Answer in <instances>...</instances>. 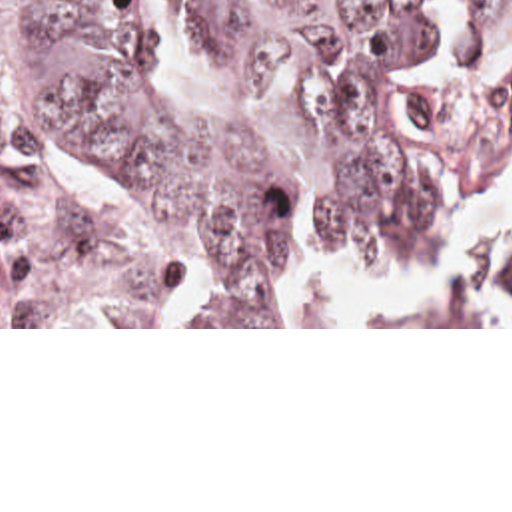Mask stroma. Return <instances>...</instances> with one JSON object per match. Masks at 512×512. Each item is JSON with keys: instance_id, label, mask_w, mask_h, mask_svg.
Wrapping results in <instances>:
<instances>
[{"instance_id": "obj_1", "label": "stroma", "mask_w": 512, "mask_h": 512, "mask_svg": "<svg viewBox=\"0 0 512 512\" xmlns=\"http://www.w3.org/2000/svg\"><path fill=\"white\" fill-rule=\"evenodd\" d=\"M18 36L14 18L0 6V121L20 115ZM0 329H512V325L411 327H273V325H0Z\"/></svg>"}]
</instances>
